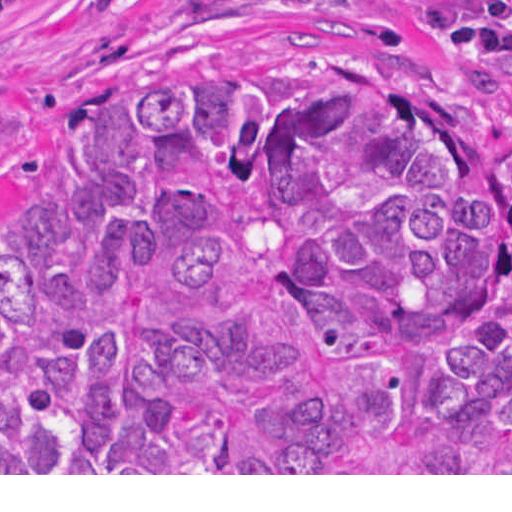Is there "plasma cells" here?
<instances>
[{
	"label": "plasma cells",
	"mask_w": 512,
	"mask_h": 512,
	"mask_svg": "<svg viewBox=\"0 0 512 512\" xmlns=\"http://www.w3.org/2000/svg\"><path fill=\"white\" fill-rule=\"evenodd\" d=\"M40 0H0V12L18 7L25 6L32 3L39 2Z\"/></svg>",
	"instance_id": "1"
}]
</instances>
